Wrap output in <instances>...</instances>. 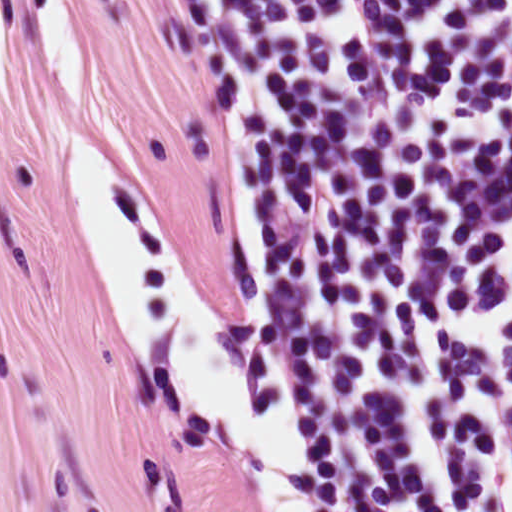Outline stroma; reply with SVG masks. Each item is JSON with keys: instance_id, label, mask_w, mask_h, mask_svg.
Instances as JSON below:
<instances>
[{"instance_id": "1", "label": "stroma", "mask_w": 512, "mask_h": 512, "mask_svg": "<svg viewBox=\"0 0 512 512\" xmlns=\"http://www.w3.org/2000/svg\"><path fill=\"white\" fill-rule=\"evenodd\" d=\"M87 92L208 300L238 309L240 259L212 117V70L172 0H54ZM57 98L25 0H0V512H278L224 419L158 375L122 322L68 194ZM269 283L308 270L287 194L286 121L260 221ZM249 341L291 423V354Z\"/></svg>"}]
</instances>
